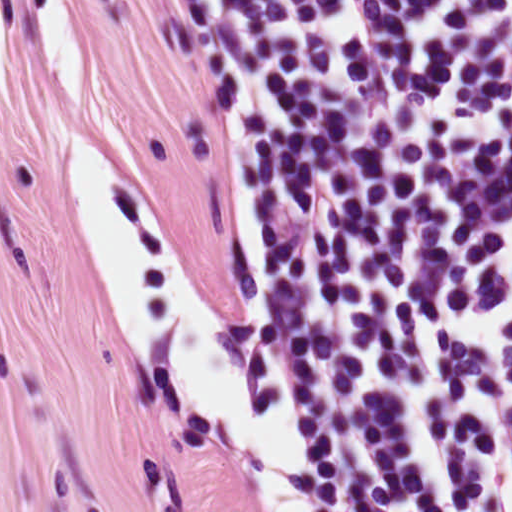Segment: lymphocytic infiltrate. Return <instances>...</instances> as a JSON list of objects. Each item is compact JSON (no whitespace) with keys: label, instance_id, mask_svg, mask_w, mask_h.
<instances>
[{"label":"lymphocytic infiltrate","instance_id":"lymphocytic-infiltrate-1","mask_svg":"<svg viewBox=\"0 0 512 512\" xmlns=\"http://www.w3.org/2000/svg\"><path fill=\"white\" fill-rule=\"evenodd\" d=\"M236 200L286 121L308 270L265 284L317 512H512V0H172Z\"/></svg>","mask_w":512,"mask_h":512}]
</instances>
